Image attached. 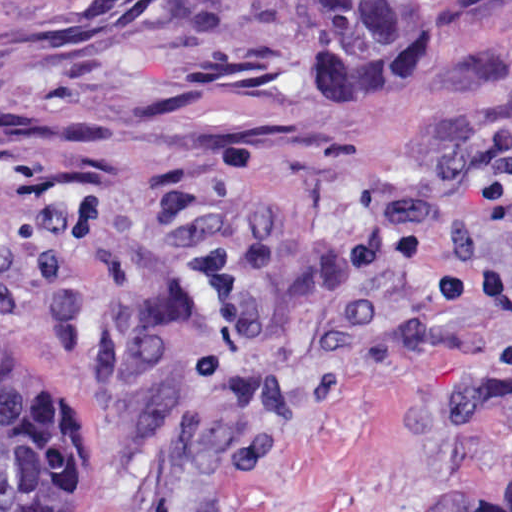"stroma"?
<instances>
[{"instance_id": "obj_1", "label": "stroma", "mask_w": 512, "mask_h": 512, "mask_svg": "<svg viewBox=\"0 0 512 512\" xmlns=\"http://www.w3.org/2000/svg\"><path fill=\"white\" fill-rule=\"evenodd\" d=\"M0 332L79 388L66 512H426L512 469V0L364 74L311 0H0Z\"/></svg>"}]
</instances>
